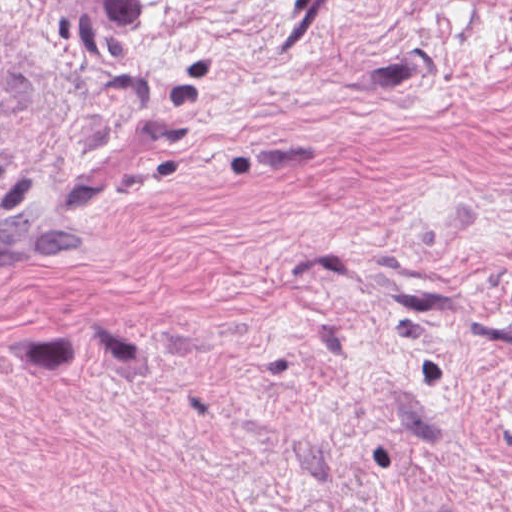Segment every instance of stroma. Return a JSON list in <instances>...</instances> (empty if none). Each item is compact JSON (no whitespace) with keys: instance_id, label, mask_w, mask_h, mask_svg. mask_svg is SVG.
I'll list each match as a JSON object with an SVG mask.
<instances>
[{"instance_id":"35a3bbf8","label":"stroma","mask_w":512,"mask_h":512,"mask_svg":"<svg viewBox=\"0 0 512 512\" xmlns=\"http://www.w3.org/2000/svg\"><path fill=\"white\" fill-rule=\"evenodd\" d=\"M0 512H512V0H0Z\"/></svg>"}]
</instances>
